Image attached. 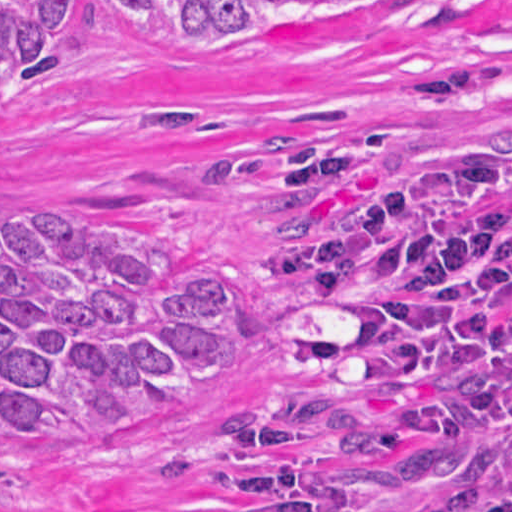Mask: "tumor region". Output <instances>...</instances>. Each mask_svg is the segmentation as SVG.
I'll return each instance as SVG.
<instances>
[{
    "instance_id": "tumor-region-1",
    "label": "tumor region",
    "mask_w": 512,
    "mask_h": 512,
    "mask_svg": "<svg viewBox=\"0 0 512 512\" xmlns=\"http://www.w3.org/2000/svg\"><path fill=\"white\" fill-rule=\"evenodd\" d=\"M420 0H99L118 46L234 63L304 29L376 21ZM82 0H0V94L49 70ZM254 327V288L86 212L0 207V441L128 427L226 370ZM0 475V489L6 477Z\"/></svg>"
}]
</instances>
